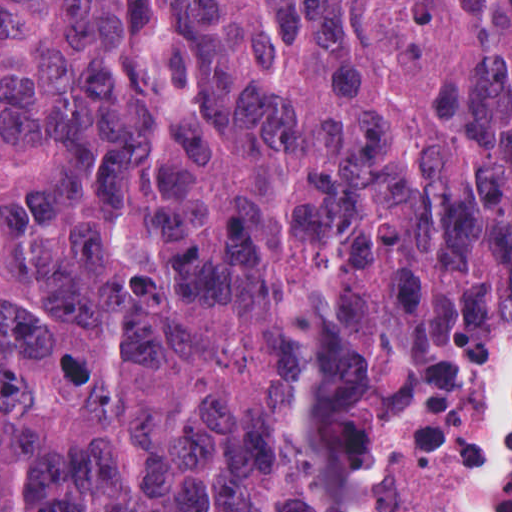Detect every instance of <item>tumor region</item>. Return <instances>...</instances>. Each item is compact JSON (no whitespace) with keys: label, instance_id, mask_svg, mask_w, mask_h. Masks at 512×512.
<instances>
[{"label":"tumor region","instance_id":"e687c5a6","mask_svg":"<svg viewBox=\"0 0 512 512\" xmlns=\"http://www.w3.org/2000/svg\"><path fill=\"white\" fill-rule=\"evenodd\" d=\"M508 2L0 0V512L354 478L459 367Z\"/></svg>","mask_w":512,"mask_h":512}]
</instances>
